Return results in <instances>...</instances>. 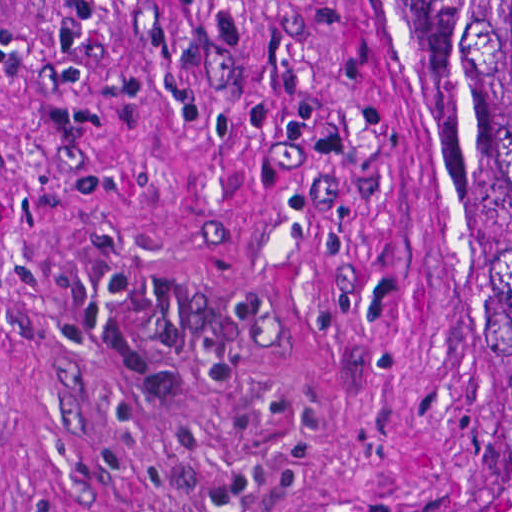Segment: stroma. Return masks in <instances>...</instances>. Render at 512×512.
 Returning a JSON list of instances; mask_svg holds the SVG:
<instances>
[{"label": "stroma", "mask_w": 512, "mask_h": 512, "mask_svg": "<svg viewBox=\"0 0 512 512\" xmlns=\"http://www.w3.org/2000/svg\"><path fill=\"white\" fill-rule=\"evenodd\" d=\"M0 512H439L415 0H0Z\"/></svg>", "instance_id": "obj_1"}]
</instances>
